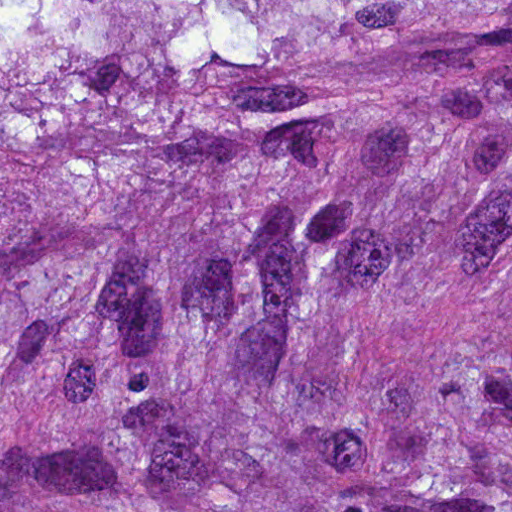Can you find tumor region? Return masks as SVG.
I'll return each mask as SVG.
<instances>
[{
	"label": "tumor region",
	"mask_w": 512,
	"mask_h": 512,
	"mask_svg": "<svg viewBox=\"0 0 512 512\" xmlns=\"http://www.w3.org/2000/svg\"><path fill=\"white\" fill-rule=\"evenodd\" d=\"M0 512H512V0H0Z\"/></svg>",
	"instance_id": "e687c5a6"
}]
</instances>
